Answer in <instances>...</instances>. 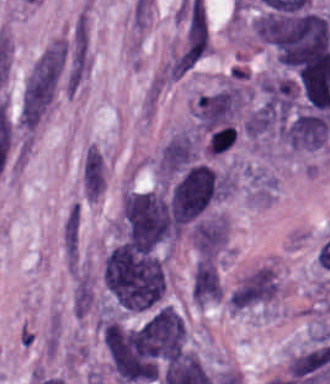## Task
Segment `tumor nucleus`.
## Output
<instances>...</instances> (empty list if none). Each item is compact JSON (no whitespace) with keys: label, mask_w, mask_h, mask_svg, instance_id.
I'll return each instance as SVG.
<instances>
[{"label":"tumor nucleus","mask_w":330,"mask_h":384,"mask_svg":"<svg viewBox=\"0 0 330 384\" xmlns=\"http://www.w3.org/2000/svg\"><path fill=\"white\" fill-rule=\"evenodd\" d=\"M102 279L119 306H156L163 300L165 271L153 251L116 246L105 255Z\"/></svg>","instance_id":"tumor-nucleus-1"},{"label":"tumor nucleus","mask_w":330,"mask_h":384,"mask_svg":"<svg viewBox=\"0 0 330 384\" xmlns=\"http://www.w3.org/2000/svg\"><path fill=\"white\" fill-rule=\"evenodd\" d=\"M118 234L121 244L150 249L178 238V226L163 191L129 189L118 220Z\"/></svg>","instance_id":"tumor-nucleus-2"},{"label":"tumor nucleus","mask_w":330,"mask_h":384,"mask_svg":"<svg viewBox=\"0 0 330 384\" xmlns=\"http://www.w3.org/2000/svg\"><path fill=\"white\" fill-rule=\"evenodd\" d=\"M237 129L233 124L221 126L215 133L211 135L209 143V151L211 153H220L231 146L236 140Z\"/></svg>","instance_id":"tumor-nucleus-3"}]
</instances>
